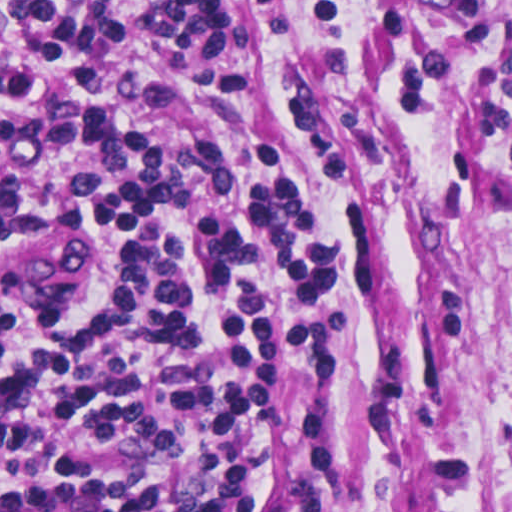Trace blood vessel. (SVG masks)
<instances>
[{"instance_id": "blood-vessel-1", "label": "blood vessel", "mask_w": 512, "mask_h": 512, "mask_svg": "<svg viewBox=\"0 0 512 512\" xmlns=\"http://www.w3.org/2000/svg\"><path fill=\"white\" fill-rule=\"evenodd\" d=\"M86 254L83 229H0V289H53L66 282Z\"/></svg>"}]
</instances>
